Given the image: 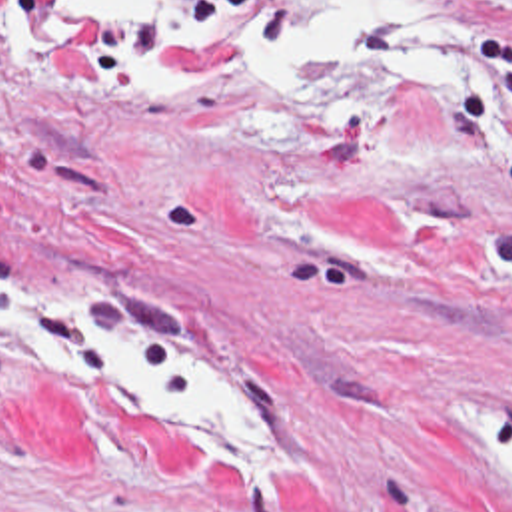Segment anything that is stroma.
Listing matches in <instances>:
<instances>
[{
  "label": "stroma",
  "instance_id": "35a3bbf8",
  "mask_svg": "<svg viewBox=\"0 0 512 512\" xmlns=\"http://www.w3.org/2000/svg\"><path fill=\"white\" fill-rule=\"evenodd\" d=\"M433 1L455 56L429 72L1 60L0 266L251 384L289 460L0 360V512H512V0Z\"/></svg>",
  "mask_w": 512,
  "mask_h": 512
}]
</instances>
